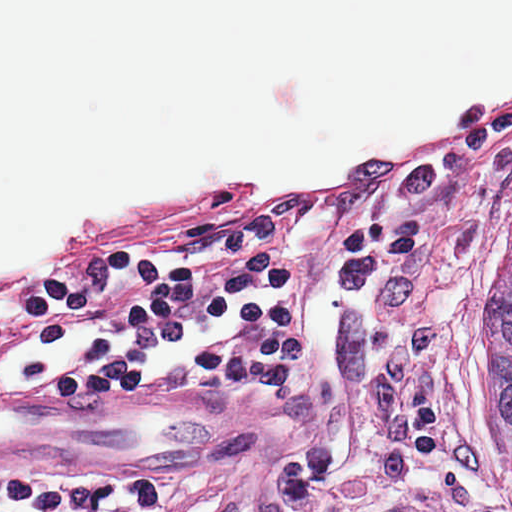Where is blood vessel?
<instances>
[{"mask_svg":"<svg viewBox=\"0 0 512 512\" xmlns=\"http://www.w3.org/2000/svg\"><path fill=\"white\" fill-rule=\"evenodd\" d=\"M228 408L168 395L0 399V459L36 467L192 466L223 459Z\"/></svg>","mask_w":512,"mask_h":512,"instance_id":"blood-vessel-1","label":"blood vessel"}]
</instances>
